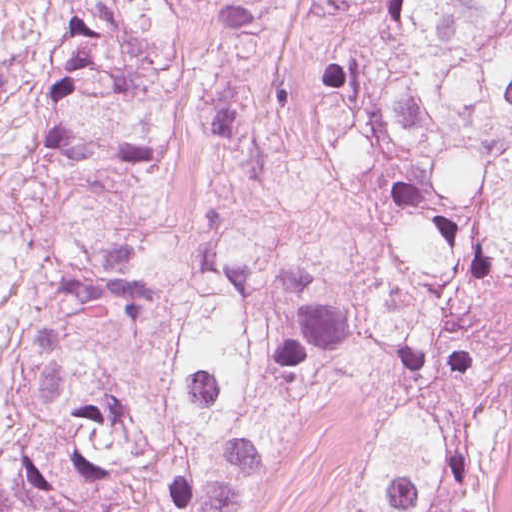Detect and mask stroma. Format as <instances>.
<instances>
[{"label":"stroma","mask_w":512,"mask_h":512,"mask_svg":"<svg viewBox=\"0 0 512 512\" xmlns=\"http://www.w3.org/2000/svg\"><path fill=\"white\" fill-rule=\"evenodd\" d=\"M83 0H0V281L68 248L94 228L132 240L152 273L172 267L203 223L240 211L239 180L206 146L203 105L214 72L212 33L180 17V43L162 102L180 126L173 158L140 187H85L61 167L39 130L48 68L61 46L80 57ZM494 367L487 424L498 450L493 512H512V301L468 322ZM371 401L365 366L331 365L277 438L263 489L244 512H341L359 431Z\"/></svg>","instance_id":"obj_1"}]
</instances>
